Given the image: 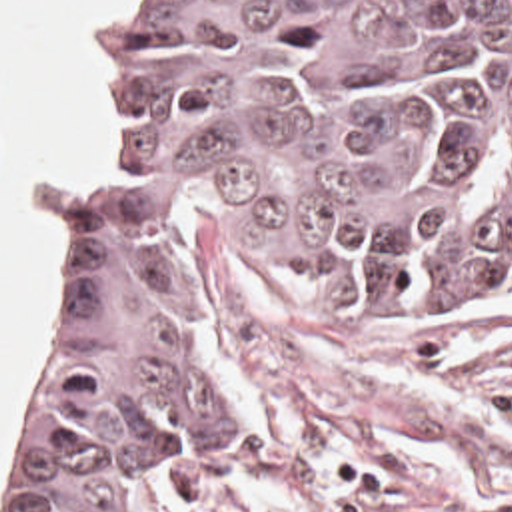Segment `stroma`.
<instances>
[{"label":"stroma","mask_w":512,"mask_h":512,"mask_svg":"<svg viewBox=\"0 0 512 512\" xmlns=\"http://www.w3.org/2000/svg\"><path fill=\"white\" fill-rule=\"evenodd\" d=\"M118 1L82 19L94 81L82 141L34 185L10 189L52 227L18 379L62 271L64 181L112 119L96 19ZM186 323L260 511L512 512V287L314 289L254 253L224 207L200 201L186 227Z\"/></svg>","instance_id":"stroma-1"}]
</instances>
